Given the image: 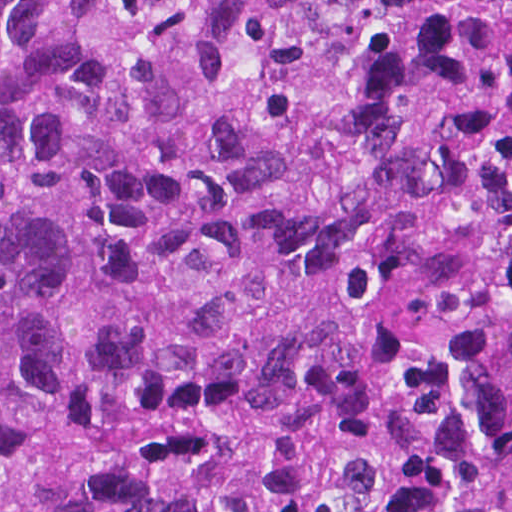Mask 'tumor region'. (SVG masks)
<instances>
[{"label": "tumor region", "mask_w": 512, "mask_h": 512, "mask_svg": "<svg viewBox=\"0 0 512 512\" xmlns=\"http://www.w3.org/2000/svg\"><path fill=\"white\" fill-rule=\"evenodd\" d=\"M0 512H512V0H0Z\"/></svg>", "instance_id": "e687c5a6"}]
</instances>
